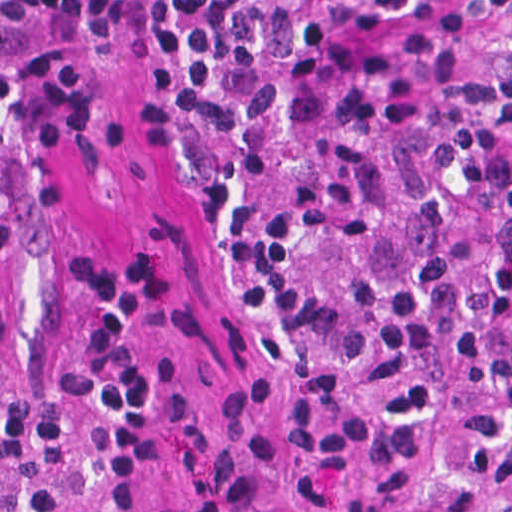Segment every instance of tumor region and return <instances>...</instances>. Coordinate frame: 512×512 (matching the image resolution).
Here are the masks:
<instances>
[{"instance_id": "1", "label": "tumor region", "mask_w": 512, "mask_h": 512, "mask_svg": "<svg viewBox=\"0 0 512 512\" xmlns=\"http://www.w3.org/2000/svg\"><path fill=\"white\" fill-rule=\"evenodd\" d=\"M77 88L71 0H0V179L34 156Z\"/></svg>"}]
</instances>
